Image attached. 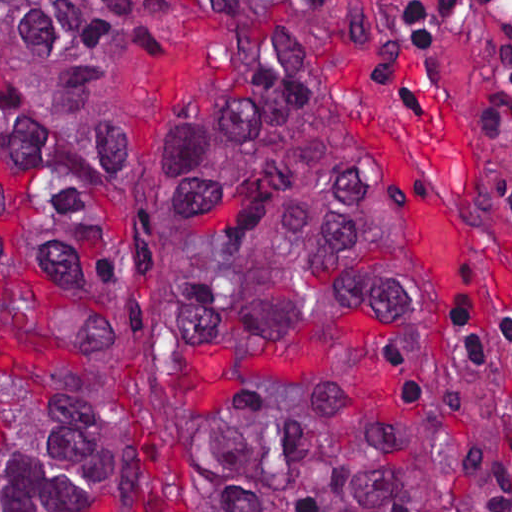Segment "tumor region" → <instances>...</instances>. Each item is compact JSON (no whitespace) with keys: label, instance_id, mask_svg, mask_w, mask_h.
<instances>
[{"label":"tumor region","instance_id":"tumor-region-1","mask_svg":"<svg viewBox=\"0 0 512 512\" xmlns=\"http://www.w3.org/2000/svg\"><path fill=\"white\" fill-rule=\"evenodd\" d=\"M212 15L171 174L131 72ZM0 512H490L460 288L298 1H0Z\"/></svg>","mask_w":512,"mask_h":512}]
</instances>
